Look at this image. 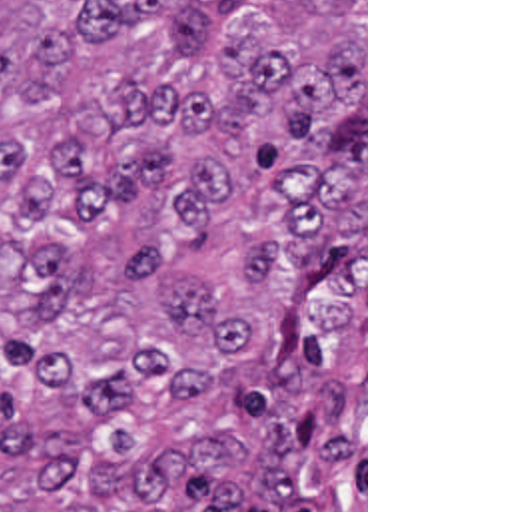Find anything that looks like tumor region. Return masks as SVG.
I'll use <instances>...</instances> for the list:
<instances>
[{
	"label": "tumor region",
	"mask_w": 512,
	"mask_h": 512,
	"mask_svg": "<svg viewBox=\"0 0 512 512\" xmlns=\"http://www.w3.org/2000/svg\"><path fill=\"white\" fill-rule=\"evenodd\" d=\"M0 512H364V0H0Z\"/></svg>",
	"instance_id": "obj_1"
}]
</instances>
